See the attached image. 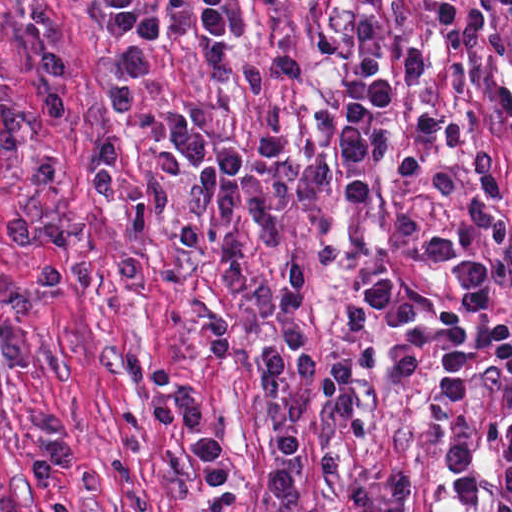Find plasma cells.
I'll list each match as a JSON object with an SVG mask.
<instances>
[{
	"instance_id": "1",
	"label": "plasma cells",
	"mask_w": 512,
	"mask_h": 512,
	"mask_svg": "<svg viewBox=\"0 0 512 512\" xmlns=\"http://www.w3.org/2000/svg\"><path fill=\"white\" fill-rule=\"evenodd\" d=\"M98 29L124 69L140 82L157 81V53L163 27L139 0H85ZM172 17L207 44V56L224 76H244L265 98L259 130V156L280 207L308 212L313 258L318 269L346 259L348 249L336 239L332 210L348 177L342 200L361 211L372 198V170L393 144L397 103V60L388 32L410 19L406 0H359V27L350 48L352 84L340 127L327 157L300 155L290 143L289 92L306 77L297 58L258 59L235 47L254 41L260 11L251 0H164ZM274 4L288 0H270ZM498 10L512 33V0H435L426 23L440 51L438 69L419 46L405 51L409 87L434 85L435 107L418 118L413 141L398 151L393 175L425 195L445 202L457 195L454 177L430 168L424 154L474 180L478 195L469 199L464 226L450 224L427 239L437 261L462 285L464 297L441 304L423 287L398 286L395 279L371 281L352 294L341 309L342 327L358 349L336 356L320 373V355L297 318L313 275L307 260L285 259L277 281L255 277L238 240V225L255 231L270 248L285 243V223L239 144L212 140L207 132L174 108L134 97L127 83L106 85L114 124L123 128L163 126L197 167L184 196L193 218L208 212L222 228L208 232L192 223L180 225L178 241L194 248L216 243L221 253V286L237 293L253 309L280 322L253 346L249 355L259 381L279 388L288 376L293 389L270 433L273 459L265 484L282 507H294L303 486L297 467L302 446L299 424L317 385L337 420L359 441L369 438L364 418L353 410L351 377L387 371L405 393L439 422L454 418L472 400L480 375L495 372L507 379L509 392L492 416L487 444L492 452L489 512H512V321L494 307L493 285L512 276V179L507 192L504 155L498 144L484 141L470 160L454 163L446 150L457 148L465 130L455 115L457 97L481 79L485 51L506 54L512 42L498 20ZM65 49L49 44L39 60L41 97L26 101L0 83V153L21 161L29 185L55 182L64 163L45 142L67 113ZM488 105L502 137L512 147V81L492 90ZM167 106V107H166ZM171 109H169V108ZM119 147L99 141L87 167L94 200L104 208L136 207L145 215L170 208L167 183L155 169L124 175ZM12 250L37 248L32 273L36 294L64 285L55 255L87 245L91 230H59L15 220L1 230ZM202 349L207 353H247L243 333L212 304L202 308ZM159 429L184 425L183 442L193 455L198 492L216 499L238 481L232 452L205 429L204 404L187 380L159 389L147 405ZM29 420L40 444L23 456L19 471L27 486L47 491L73 469L72 435L66 416L31 410ZM446 477L457 500L468 507L483 499L479 474V434L456 441L446 450ZM416 474L395 454L379 456L341 503L342 512H413Z\"/></svg>"
}]
</instances>
